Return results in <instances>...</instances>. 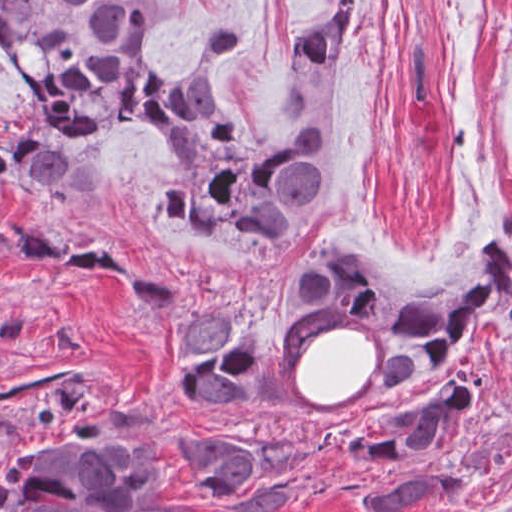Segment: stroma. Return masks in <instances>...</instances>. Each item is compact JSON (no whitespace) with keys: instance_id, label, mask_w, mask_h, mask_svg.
<instances>
[{"instance_id":"35a3bbf8","label":"stroma","mask_w":512,"mask_h":512,"mask_svg":"<svg viewBox=\"0 0 512 512\" xmlns=\"http://www.w3.org/2000/svg\"><path fill=\"white\" fill-rule=\"evenodd\" d=\"M336 2L164 0L154 18V61L179 74L197 59L210 65L209 34L241 16L219 98L255 139L344 134L324 199L270 267H240L203 232L148 221L145 196L167 161L166 140L148 129L107 137L108 200L97 212L23 192L0 197L8 231L19 217L59 243L103 240L149 276L179 284L189 311L226 300L268 350L273 406L179 403L161 378L172 324L156 321L124 283L32 263L0 264V389L77 372L94 410L142 427L150 459L166 462L159 497L181 508L215 512L180 451L209 431L323 459L308 494L286 512H361L355 490L371 471L312 449L314 429L471 372L486 402L451 455L453 489L416 512H512V311L489 305L439 377L381 393L383 327L330 317L294 332L274 298L288 263L307 248L353 251L389 287L415 292L448 277L483 233L512 247V0H360V48L339 66L304 69L299 44ZM27 100L0 60V118ZM31 428L25 404L0 406V449Z\"/></svg>"}]
</instances>
